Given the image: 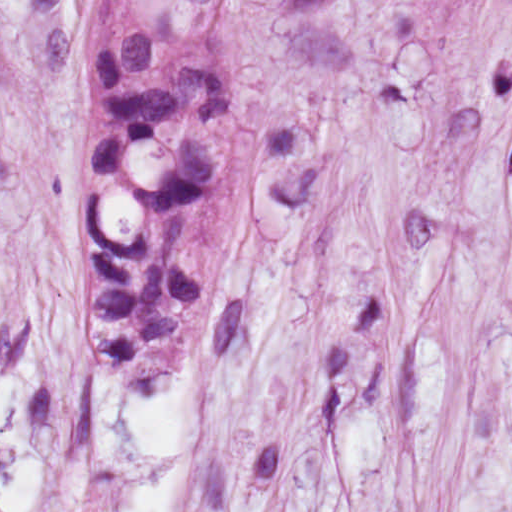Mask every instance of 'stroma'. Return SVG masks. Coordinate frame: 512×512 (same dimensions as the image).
<instances>
[{"instance_id": "1", "label": "stroma", "mask_w": 512, "mask_h": 512, "mask_svg": "<svg viewBox=\"0 0 512 512\" xmlns=\"http://www.w3.org/2000/svg\"><path fill=\"white\" fill-rule=\"evenodd\" d=\"M104 0H0V512H512V0H242L236 231L171 385L83 313Z\"/></svg>"}]
</instances>
